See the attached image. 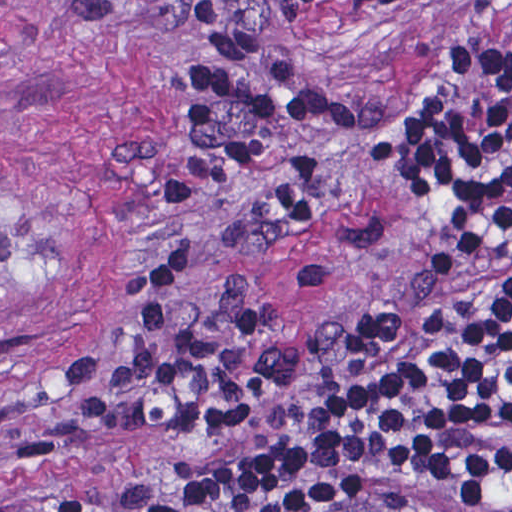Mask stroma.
I'll list each match as a JSON object with an SVG mask.
<instances>
[{"label":"stroma","mask_w":512,"mask_h":512,"mask_svg":"<svg viewBox=\"0 0 512 512\" xmlns=\"http://www.w3.org/2000/svg\"><path fill=\"white\" fill-rule=\"evenodd\" d=\"M227 44L345 106L427 115L450 63L512 66V0H0V512H71L169 461L174 436L76 410L71 383L145 247L197 248L285 348L371 328L352 233L239 224L168 164L173 72Z\"/></svg>","instance_id":"1"}]
</instances>
